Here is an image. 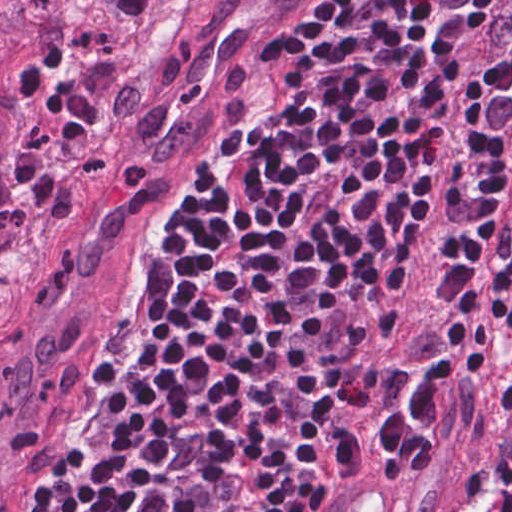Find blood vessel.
I'll list each match as a JSON object with an SVG mask.
<instances>
[{
	"label": "blood vessel",
	"mask_w": 512,
	"mask_h": 512,
	"mask_svg": "<svg viewBox=\"0 0 512 512\" xmlns=\"http://www.w3.org/2000/svg\"><path fill=\"white\" fill-rule=\"evenodd\" d=\"M330 512H400V500L376 471L361 472L351 479Z\"/></svg>",
	"instance_id": "8fb6f2fc"
}]
</instances>
